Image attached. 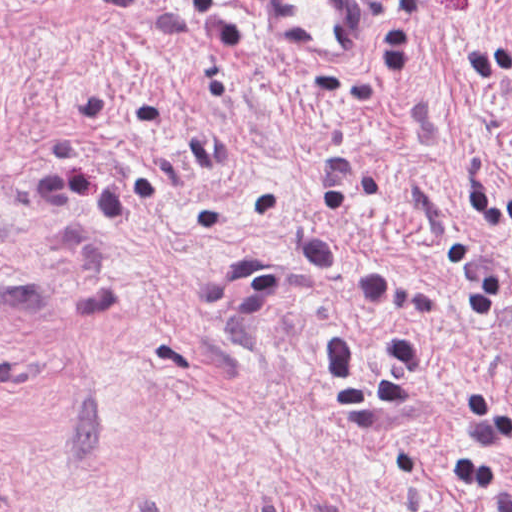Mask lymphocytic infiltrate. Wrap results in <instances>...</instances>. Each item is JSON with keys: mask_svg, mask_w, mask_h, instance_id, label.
Wrapping results in <instances>:
<instances>
[{"mask_svg": "<svg viewBox=\"0 0 512 512\" xmlns=\"http://www.w3.org/2000/svg\"><path fill=\"white\" fill-rule=\"evenodd\" d=\"M320 385L341 414H387L414 400L424 374V351L413 337L389 340L374 370V385L357 374L353 346L344 326L327 328L318 345ZM467 439L446 452L449 474L473 487L492 512H512V480L500 464V448L511 433L496 390L482 383L464 385Z\"/></svg>", "mask_w": 512, "mask_h": 512, "instance_id": "obj_1", "label": "lymphocytic infiltrate"}]
</instances>
